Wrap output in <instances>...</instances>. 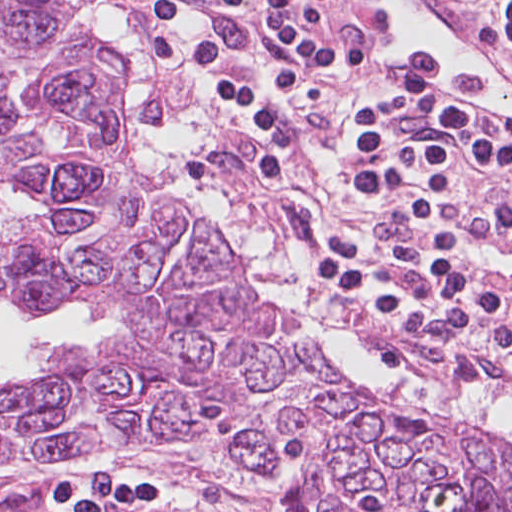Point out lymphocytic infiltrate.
I'll list each match as a JSON object with an SVG mask.
<instances>
[{"mask_svg":"<svg viewBox=\"0 0 512 512\" xmlns=\"http://www.w3.org/2000/svg\"><path fill=\"white\" fill-rule=\"evenodd\" d=\"M467 26L512 54V0H445ZM358 0H155L151 51L213 95L224 121H306L329 94L354 121L457 114L410 89L354 75ZM453 226L416 172V152L386 127H354L351 162L377 244L334 235L311 267L323 293L364 301L383 329L414 335L433 312L452 341L477 350L512 383V293L472 248L512 277V142L474 128L409 129ZM306 127L237 139L261 177L282 184Z\"/></svg>","mask_w":512,"mask_h":512,"instance_id":"f902f5d3","label":"lymphocytic infiltrate"}]
</instances>
